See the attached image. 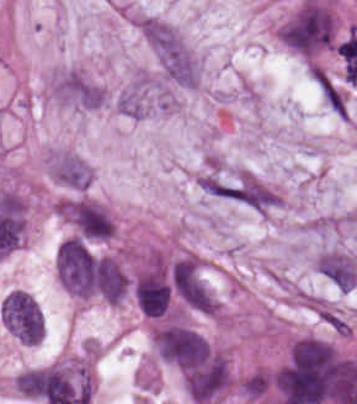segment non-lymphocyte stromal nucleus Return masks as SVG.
<instances>
[{
    "label": "non-lymphocyte stromal nucleus",
    "instance_id": "obj_1",
    "mask_svg": "<svg viewBox=\"0 0 357 404\" xmlns=\"http://www.w3.org/2000/svg\"><path fill=\"white\" fill-rule=\"evenodd\" d=\"M142 32L167 78L180 85H194L199 65L181 35L160 20H147Z\"/></svg>",
    "mask_w": 357,
    "mask_h": 404
}]
</instances>
